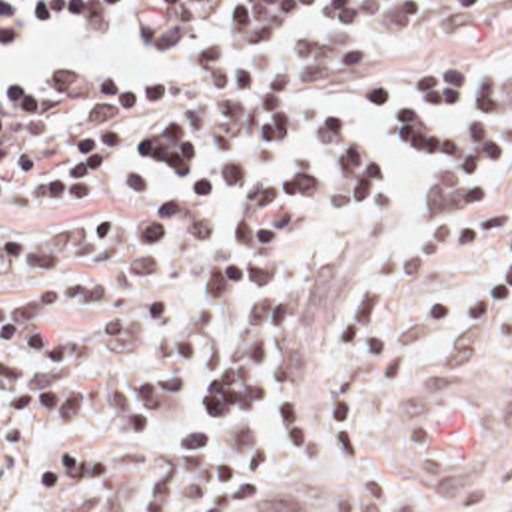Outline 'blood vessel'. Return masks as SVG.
I'll return each instance as SVG.
<instances>
[{
    "label": "blood vessel",
    "mask_w": 512,
    "mask_h": 512,
    "mask_svg": "<svg viewBox=\"0 0 512 512\" xmlns=\"http://www.w3.org/2000/svg\"><path fill=\"white\" fill-rule=\"evenodd\" d=\"M398 425L412 453L446 475H484L506 455V397L470 373L418 371Z\"/></svg>",
    "instance_id": "1"
}]
</instances>
